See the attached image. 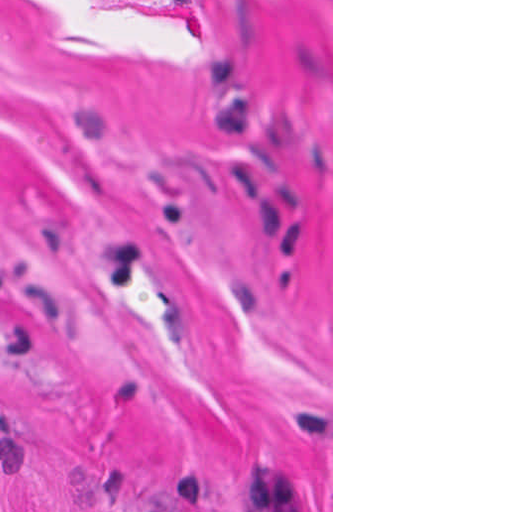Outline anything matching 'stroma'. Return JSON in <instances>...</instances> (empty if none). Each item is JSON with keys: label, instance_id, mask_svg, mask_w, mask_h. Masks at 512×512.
<instances>
[{"label": "stroma", "instance_id": "stroma-1", "mask_svg": "<svg viewBox=\"0 0 512 512\" xmlns=\"http://www.w3.org/2000/svg\"><path fill=\"white\" fill-rule=\"evenodd\" d=\"M0 512H333V0H0Z\"/></svg>", "mask_w": 512, "mask_h": 512}]
</instances>
